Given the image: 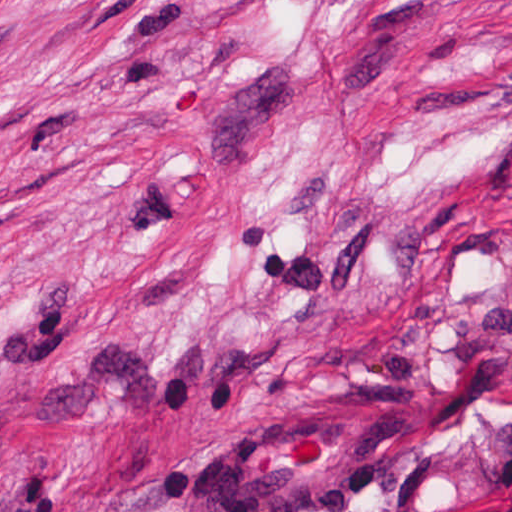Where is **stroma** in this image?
I'll return each instance as SVG.
<instances>
[{"label": "stroma", "instance_id": "35a3bbf8", "mask_svg": "<svg viewBox=\"0 0 512 512\" xmlns=\"http://www.w3.org/2000/svg\"><path fill=\"white\" fill-rule=\"evenodd\" d=\"M312 409L338 512L512 510V0H0V512Z\"/></svg>", "mask_w": 512, "mask_h": 512}]
</instances>
